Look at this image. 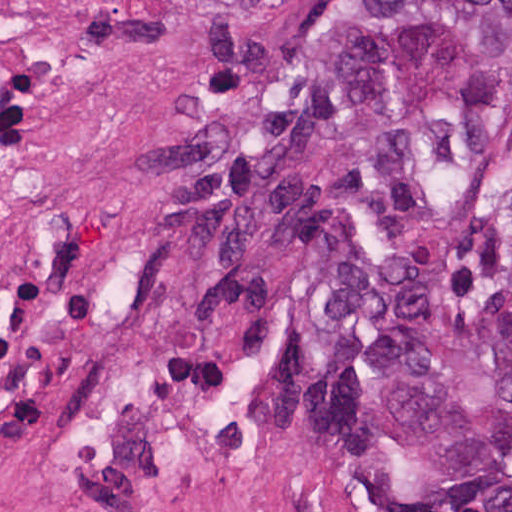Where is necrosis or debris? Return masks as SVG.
Segmentation results:
<instances>
[{"mask_svg":"<svg viewBox=\"0 0 512 512\" xmlns=\"http://www.w3.org/2000/svg\"><path fill=\"white\" fill-rule=\"evenodd\" d=\"M181 139L152 64L25 0H0V343L104 251Z\"/></svg>","mask_w":512,"mask_h":512,"instance_id":"necrosis-or-debris-1","label":"necrosis or debris"}]
</instances>
